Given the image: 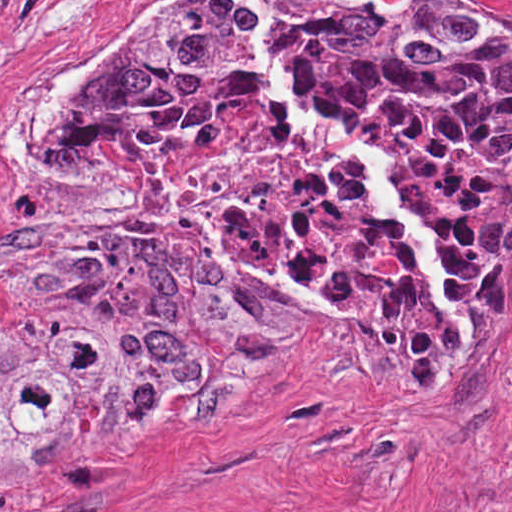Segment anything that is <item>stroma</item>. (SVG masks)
<instances>
[{"mask_svg": "<svg viewBox=\"0 0 512 512\" xmlns=\"http://www.w3.org/2000/svg\"><path fill=\"white\" fill-rule=\"evenodd\" d=\"M176 1L46 0L0 127V255L40 225L74 109ZM461 1L512 19V0ZM24 302L0 296V341ZM0 512H512V281L430 350L378 311L331 309L189 433L0 473Z\"/></svg>", "mask_w": 512, "mask_h": 512, "instance_id": "35a3bbf8", "label": "stroma"}]
</instances>
